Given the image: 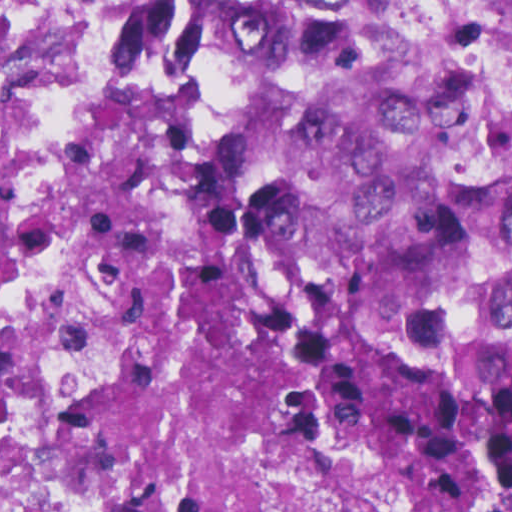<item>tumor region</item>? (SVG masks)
Segmentation results:
<instances>
[{
	"instance_id": "1",
	"label": "tumor region",
	"mask_w": 512,
	"mask_h": 512,
	"mask_svg": "<svg viewBox=\"0 0 512 512\" xmlns=\"http://www.w3.org/2000/svg\"><path fill=\"white\" fill-rule=\"evenodd\" d=\"M64 231L166 512H512V0H117L0 104V288Z\"/></svg>"
}]
</instances>
